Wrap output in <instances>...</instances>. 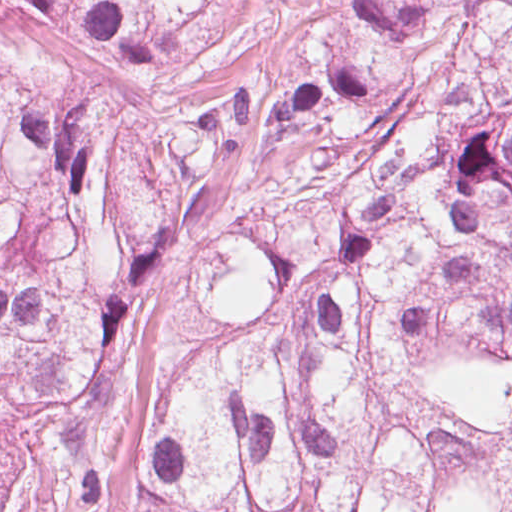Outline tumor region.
Segmentation results:
<instances>
[{
  "mask_svg": "<svg viewBox=\"0 0 512 512\" xmlns=\"http://www.w3.org/2000/svg\"><path fill=\"white\" fill-rule=\"evenodd\" d=\"M512 355V0H0V512H461Z\"/></svg>",
  "mask_w": 512,
  "mask_h": 512,
  "instance_id": "tumor-region-1",
  "label": "tumor region"
}]
</instances>
